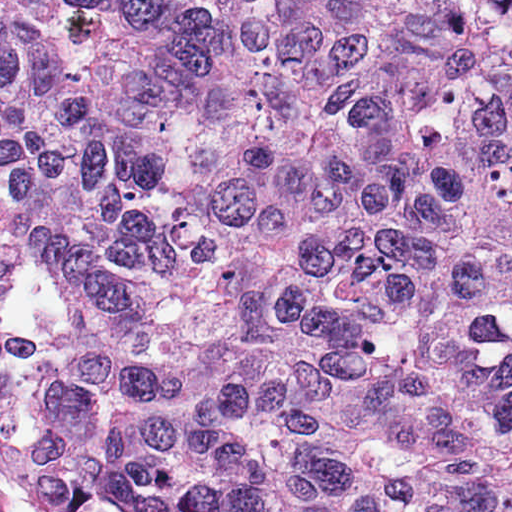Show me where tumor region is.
Instances as JSON below:
<instances>
[{
	"instance_id": "tumor-region-1",
	"label": "tumor region",
	"mask_w": 512,
	"mask_h": 512,
	"mask_svg": "<svg viewBox=\"0 0 512 512\" xmlns=\"http://www.w3.org/2000/svg\"><path fill=\"white\" fill-rule=\"evenodd\" d=\"M0 203L134 505L512 512V0H0Z\"/></svg>"
}]
</instances>
